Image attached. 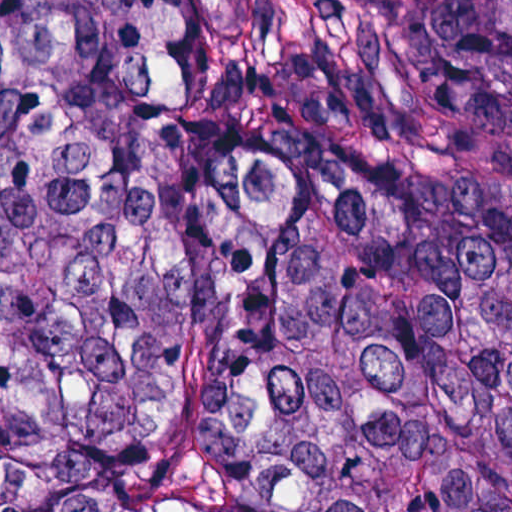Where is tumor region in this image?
Here are the masks:
<instances>
[{
	"mask_svg": "<svg viewBox=\"0 0 512 512\" xmlns=\"http://www.w3.org/2000/svg\"><path fill=\"white\" fill-rule=\"evenodd\" d=\"M0 512H512V0H0Z\"/></svg>",
	"mask_w": 512,
	"mask_h": 512,
	"instance_id": "tumor-region-1",
	"label": "tumor region"
}]
</instances>
